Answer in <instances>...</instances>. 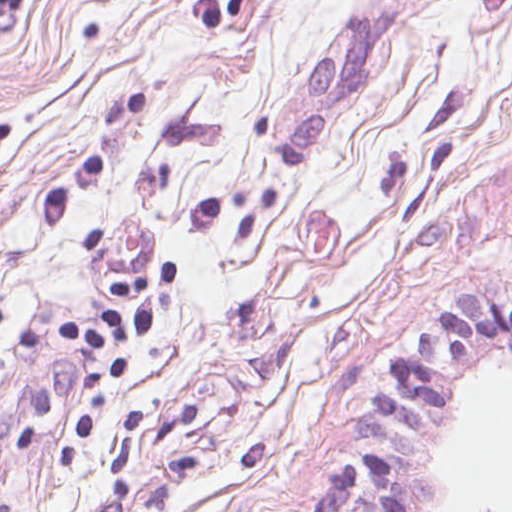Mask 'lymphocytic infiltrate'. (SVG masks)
<instances>
[{"label": "lymphocytic infiltrate", "instance_id": "f902f5d3", "mask_svg": "<svg viewBox=\"0 0 512 512\" xmlns=\"http://www.w3.org/2000/svg\"><path fill=\"white\" fill-rule=\"evenodd\" d=\"M175 280L176 262L170 260L120 278L106 288L93 318L66 322L58 337L66 345L121 349L149 332L156 292ZM492 342L512 347V301L487 293L452 299L440 318L384 358L386 383L371 398L375 408L404 431L427 429L434 409L445 405L453 376L465 366L467 354ZM371 469L386 512H407L393 467L377 448Z\"/></svg>", "mask_w": 512, "mask_h": 512}]
</instances>
